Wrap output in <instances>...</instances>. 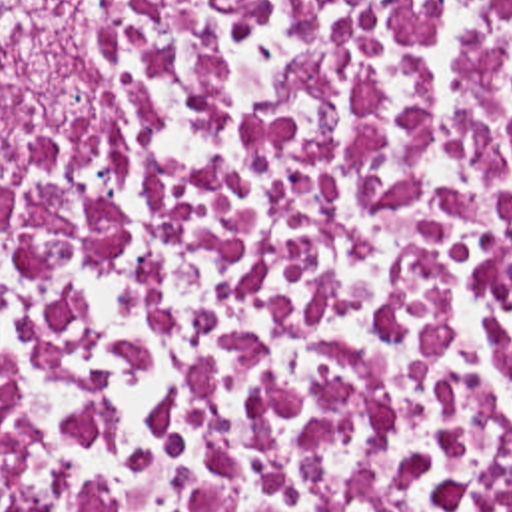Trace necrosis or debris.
<instances>
[{
    "instance_id": "obj_1",
    "label": "necrosis or debris",
    "mask_w": 512,
    "mask_h": 512,
    "mask_svg": "<svg viewBox=\"0 0 512 512\" xmlns=\"http://www.w3.org/2000/svg\"><path fill=\"white\" fill-rule=\"evenodd\" d=\"M0 512H512V0H0Z\"/></svg>"
}]
</instances>
